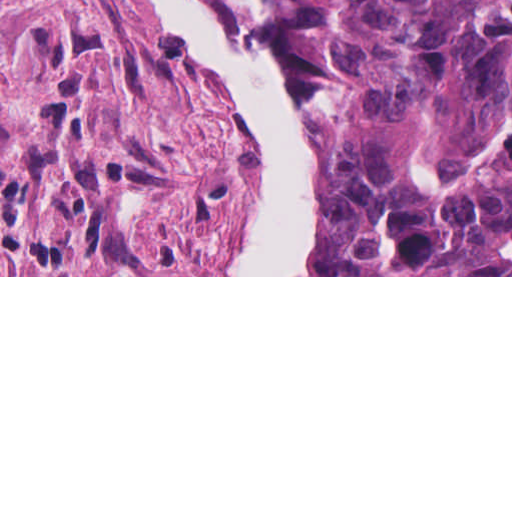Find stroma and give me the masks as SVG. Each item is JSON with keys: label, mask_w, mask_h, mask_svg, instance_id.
Wrapping results in <instances>:
<instances>
[{"label": "stroma", "mask_w": 512, "mask_h": 512, "mask_svg": "<svg viewBox=\"0 0 512 512\" xmlns=\"http://www.w3.org/2000/svg\"><path fill=\"white\" fill-rule=\"evenodd\" d=\"M223 1L301 99L306 275H211L240 215V127L142 0H0V277H512L309 275L315 99L263 0Z\"/></svg>", "instance_id": "1"}]
</instances>
